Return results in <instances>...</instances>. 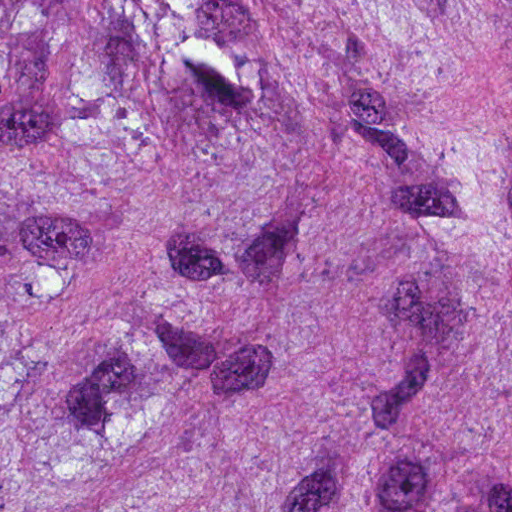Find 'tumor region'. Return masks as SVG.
I'll return each instance as SVG.
<instances>
[{
	"instance_id": "tumor-region-1",
	"label": "tumor region",
	"mask_w": 512,
	"mask_h": 512,
	"mask_svg": "<svg viewBox=\"0 0 512 512\" xmlns=\"http://www.w3.org/2000/svg\"><path fill=\"white\" fill-rule=\"evenodd\" d=\"M0 512H512V0H0Z\"/></svg>"
}]
</instances>
